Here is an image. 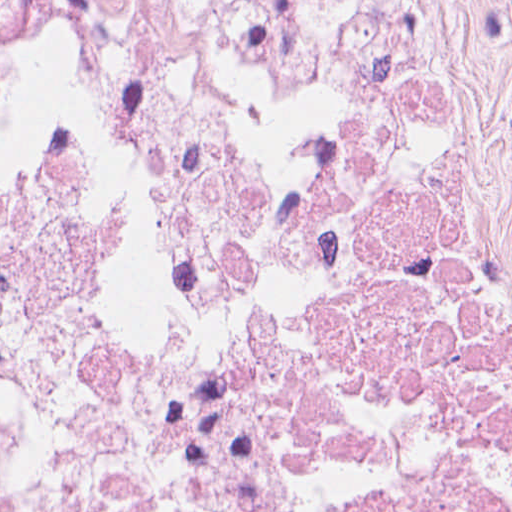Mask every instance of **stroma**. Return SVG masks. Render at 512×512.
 Listing matches in <instances>:
<instances>
[{
  "label": "stroma",
  "mask_w": 512,
  "mask_h": 512,
  "mask_svg": "<svg viewBox=\"0 0 512 512\" xmlns=\"http://www.w3.org/2000/svg\"><path fill=\"white\" fill-rule=\"evenodd\" d=\"M434 54L465 237L512 319V0H399ZM512 403L471 512H501Z\"/></svg>",
  "instance_id": "1"
}]
</instances>
